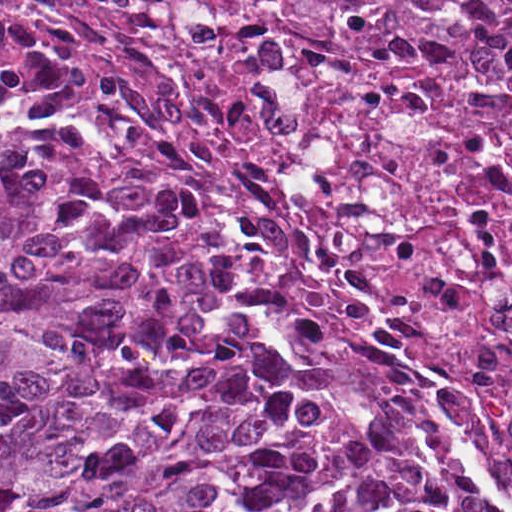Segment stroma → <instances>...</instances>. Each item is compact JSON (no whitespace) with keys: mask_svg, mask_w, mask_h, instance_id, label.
<instances>
[{"mask_svg":"<svg viewBox=\"0 0 512 512\" xmlns=\"http://www.w3.org/2000/svg\"><path fill=\"white\" fill-rule=\"evenodd\" d=\"M0 1H512V0H0ZM0 112L22 121H40L67 125L75 128L96 141L125 171L145 198L152 216L186 250L196 264L209 276L219 294L235 301L248 317L263 339L276 344H294L310 350L328 363L340 376L363 390L370 400L380 407L390 421L412 436L432 465L440 484L433 496L437 512H449L455 483L447 458L431 443L419 422L397 405L393 400L380 396L360 380L348 374L331 356L327 349L308 346L300 342H284L267 327L244 299L241 290L232 277L219 269L211 257L184 231L178 219L166 210L158 192L150 180L137 168L133 155L125 145L110 136L97 125H82L61 119L46 112L24 110L0 98Z\"/></svg>","mask_w":512,"mask_h":512,"instance_id":"1","label":"stroma"}]
</instances>
